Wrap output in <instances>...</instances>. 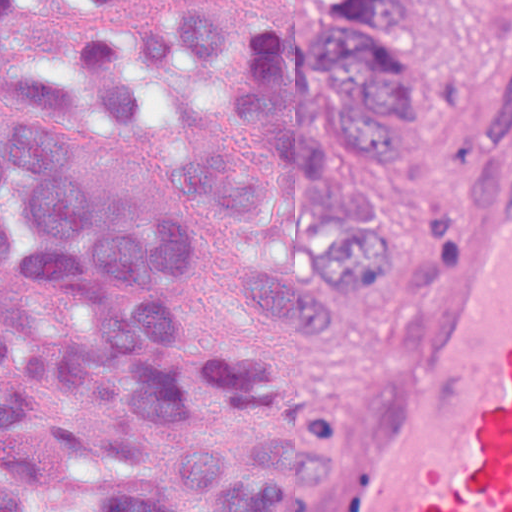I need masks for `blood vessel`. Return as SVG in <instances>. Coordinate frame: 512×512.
Returning <instances> with one entry per match:
<instances>
[{"mask_svg": "<svg viewBox=\"0 0 512 512\" xmlns=\"http://www.w3.org/2000/svg\"><path fill=\"white\" fill-rule=\"evenodd\" d=\"M301 512H512V0L449 231L399 357Z\"/></svg>", "mask_w": 512, "mask_h": 512, "instance_id": "blood-vessel-1", "label": "blood vessel"}]
</instances>
